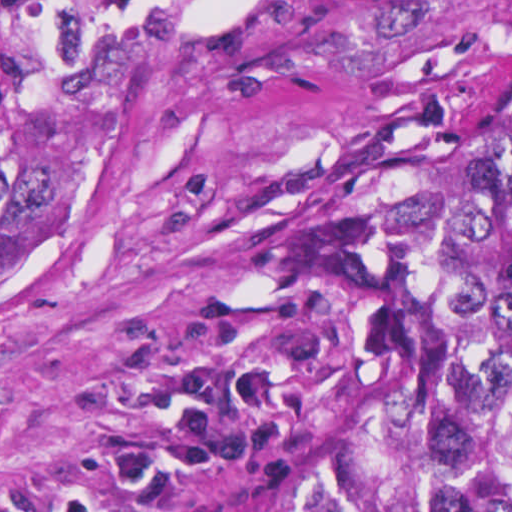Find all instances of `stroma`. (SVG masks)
<instances>
[{"mask_svg":"<svg viewBox=\"0 0 512 512\" xmlns=\"http://www.w3.org/2000/svg\"><path fill=\"white\" fill-rule=\"evenodd\" d=\"M480 70L512 93V0H150L103 164L0 286V512H283L394 114Z\"/></svg>","mask_w":512,"mask_h":512,"instance_id":"35a3bbf8","label":"stroma"}]
</instances>
